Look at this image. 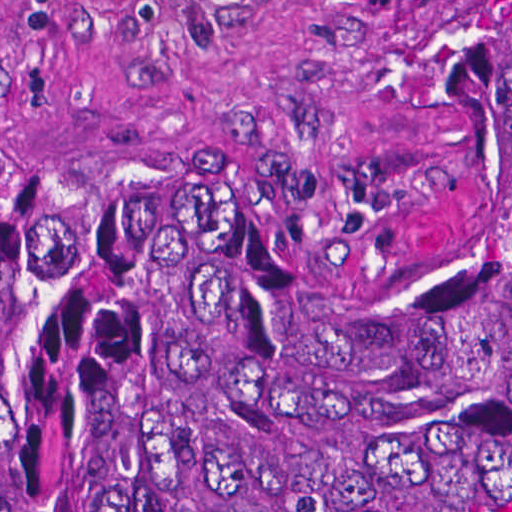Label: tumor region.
I'll return each instance as SVG.
<instances>
[{"instance_id": "tumor-region-1", "label": "tumor region", "mask_w": 512, "mask_h": 512, "mask_svg": "<svg viewBox=\"0 0 512 512\" xmlns=\"http://www.w3.org/2000/svg\"><path fill=\"white\" fill-rule=\"evenodd\" d=\"M434 279L267 188L0 176V512H512V0H439Z\"/></svg>"}]
</instances>
